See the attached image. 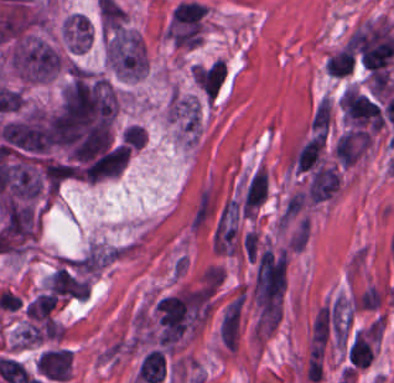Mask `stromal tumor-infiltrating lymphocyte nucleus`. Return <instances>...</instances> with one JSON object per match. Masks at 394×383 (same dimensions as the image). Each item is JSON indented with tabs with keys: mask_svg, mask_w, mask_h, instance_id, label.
Returning <instances> with one entry per match:
<instances>
[{
	"mask_svg": "<svg viewBox=\"0 0 394 383\" xmlns=\"http://www.w3.org/2000/svg\"><path fill=\"white\" fill-rule=\"evenodd\" d=\"M354 366L365 367L373 357L372 329L356 331L348 352Z\"/></svg>",
	"mask_w": 394,
	"mask_h": 383,
	"instance_id": "1",
	"label": "stromal tumor-infiltrating lymphocyte nucleus"
}]
</instances>
